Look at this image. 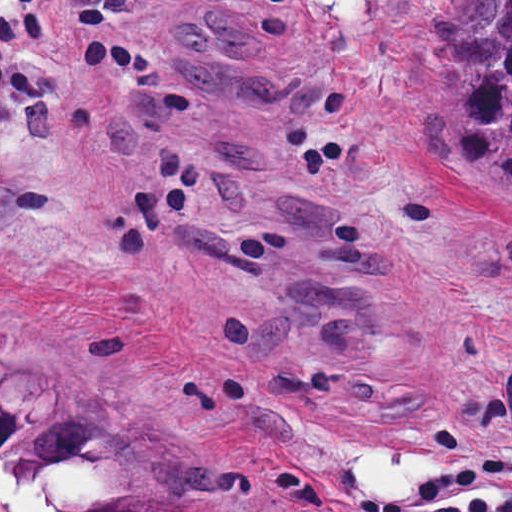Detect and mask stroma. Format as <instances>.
<instances>
[{
	"instance_id": "35a3bbf8",
	"label": "stroma",
	"mask_w": 512,
	"mask_h": 512,
	"mask_svg": "<svg viewBox=\"0 0 512 512\" xmlns=\"http://www.w3.org/2000/svg\"><path fill=\"white\" fill-rule=\"evenodd\" d=\"M460 2L0 0V341L236 464L217 512H512Z\"/></svg>"
}]
</instances>
